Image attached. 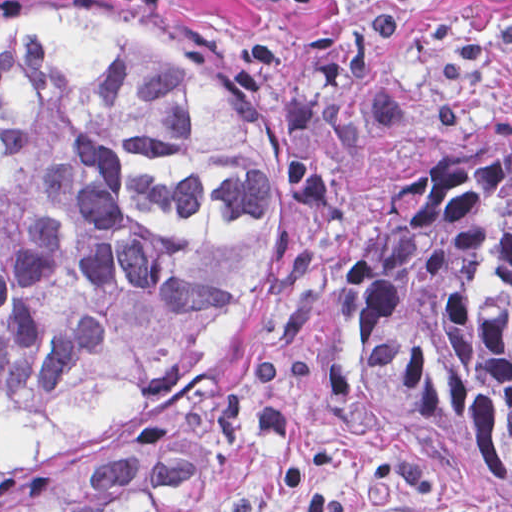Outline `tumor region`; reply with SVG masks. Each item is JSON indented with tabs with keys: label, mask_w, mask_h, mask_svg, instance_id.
Here are the masks:
<instances>
[{
	"label": "tumor region",
	"mask_w": 512,
	"mask_h": 512,
	"mask_svg": "<svg viewBox=\"0 0 512 512\" xmlns=\"http://www.w3.org/2000/svg\"><path fill=\"white\" fill-rule=\"evenodd\" d=\"M255 100L121 9H1V512H214L217 377L275 257ZM339 387L512 488V145L453 156Z\"/></svg>",
	"instance_id": "tumor-region-1"
}]
</instances>
